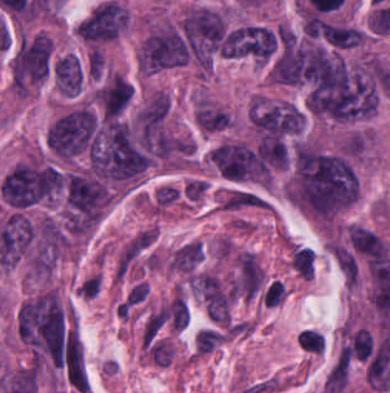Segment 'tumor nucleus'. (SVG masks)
I'll return each instance as SVG.
<instances>
[{
	"label": "tumor nucleus",
	"mask_w": 390,
	"mask_h": 393,
	"mask_svg": "<svg viewBox=\"0 0 390 393\" xmlns=\"http://www.w3.org/2000/svg\"><path fill=\"white\" fill-rule=\"evenodd\" d=\"M359 189L355 168L348 157L297 143L285 188L292 203L327 221L350 206Z\"/></svg>",
	"instance_id": "2f306a5c"
},
{
	"label": "tumor nucleus",
	"mask_w": 390,
	"mask_h": 393,
	"mask_svg": "<svg viewBox=\"0 0 390 393\" xmlns=\"http://www.w3.org/2000/svg\"><path fill=\"white\" fill-rule=\"evenodd\" d=\"M99 133L98 119L88 105L58 115L46 128L44 142L56 157L73 158L89 151Z\"/></svg>",
	"instance_id": "8643909e"
},
{
	"label": "tumor nucleus",
	"mask_w": 390,
	"mask_h": 393,
	"mask_svg": "<svg viewBox=\"0 0 390 393\" xmlns=\"http://www.w3.org/2000/svg\"><path fill=\"white\" fill-rule=\"evenodd\" d=\"M191 58L188 43L179 24H166L147 33L140 42L137 63L153 72L186 64Z\"/></svg>",
	"instance_id": "5ab6c2c4"
},
{
	"label": "tumor nucleus",
	"mask_w": 390,
	"mask_h": 393,
	"mask_svg": "<svg viewBox=\"0 0 390 393\" xmlns=\"http://www.w3.org/2000/svg\"><path fill=\"white\" fill-rule=\"evenodd\" d=\"M64 192L68 226H88L102 217L107 191L95 176L68 172Z\"/></svg>",
	"instance_id": "2cbd58db"
},
{
	"label": "tumor nucleus",
	"mask_w": 390,
	"mask_h": 393,
	"mask_svg": "<svg viewBox=\"0 0 390 393\" xmlns=\"http://www.w3.org/2000/svg\"><path fill=\"white\" fill-rule=\"evenodd\" d=\"M52 42L45 34H37L17 49L10 65L15 92H25L48 74Z\"/></svg>",
	"instance_id": "3d1891a8"
},
{
	"label": "tumor nucleus",
	"mask_w": 390,
	"mask_h": 393,
	"mask_svg": "<svg viewBox=\"0 0 390 393\" xmlns=\"http://www.w3.org/2000/svg\"><path fill=\"white\" fill-rule=\"evenodd\" d=\"M217 170L233 181H267V162L242 143L223 142L211 151Z\"/></svg>",
	"instance_id": "2083b535"
},
{
	"label": "tumor nucleus",
	"mask_w": 390,
	"mask_h": 393,
	"mask_svg": "<svg viewBox=\"0 0 390 393\" xmlns=\"http://www.w3.org/2000/svg\"><path fill=\"white\" fill-rule=\"evenodd\" d=\"M251 123L267 137H280L300 131L302 112L291 101L256 99L249 110Z\"/></svg>",
	"instance_id": "8087334f"
},
{
	"label": "tumor nucleus",
	"mask_w": 390,
	"mask_h": 393,
	"mask_svg": "<svg viewBox=\"0 0 390 393\" xmlns=\"http://www.w3.org/2000/svg\"><path fill=\"white\" fill-rule=\"evenodd\" d=\"M126 24L127 16L123 8L114 1H107L77 24V32L89 46L99 48L118 38Z\"/></svg>",
	"instance_id": "c2bd9aea"
},
{
	"label": "tumor nucleus",
	"mask_w": 390,
	"mask_h": 393,
	"mask_svg": "<svg viewBox=\"0 0 390 393\" xmlns=\"http://www.w3.org/2000/svg\"><path fill=\"white\" fill-rule=\"evenodd\" d=\"M258 54V29L253 24H240L226 34L221 57L254 58Z\"/></svg>",
	"instance_id": "feef74b5"
},
{
	"label": "tumor nucleus",
	"mask_w": 390,
	"mask_h": 393,
	"mask_svg": "<svg viewBox=\"0 0 390 393\" xmlns=\"http://www.w3.org/2000/svg\"><path fill=\"white\" fill-rule=\"evenodd\" d=\"M83 70L78 56L66 54L54 63V78L64 94H78L82 84Z\"/></svg>",
	"instance_id": "3e47fb67"
}]
</instances>
